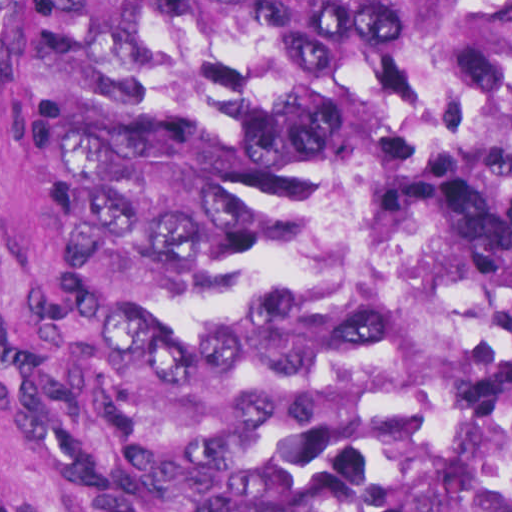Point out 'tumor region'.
Returning a JSON list of instances; mask_svg holds the SVG:
<instances>
[{
    "mask_svg": "<svg viewBox=\"0 0 512 512\" xmlns=\"http://www.w3.org/2000/svg\"><path fill=\"white\" fill-rule=\"evenodd\" d=\"M27 428L68 512H512V1H1Z\"/></svg>",
    "mask_w": 512,
    "mask_h": 512,
    "instance_id": "1",
    "label": "tumor region"
}]
</instances>
